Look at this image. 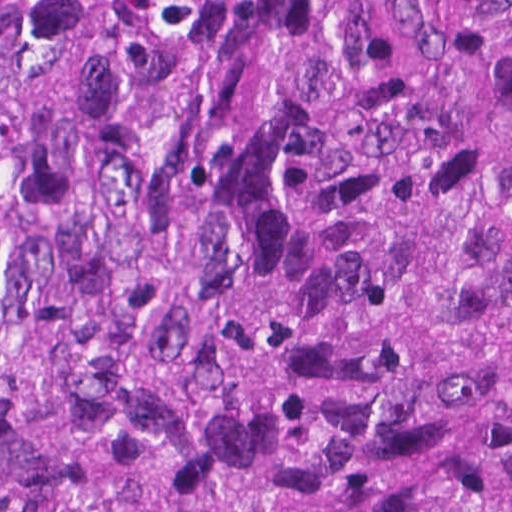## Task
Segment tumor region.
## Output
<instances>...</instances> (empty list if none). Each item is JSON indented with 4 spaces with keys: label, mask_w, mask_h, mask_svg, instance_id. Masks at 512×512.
Here are the masks:
<instances>
[{
    "label": "tumor region",
    "mask_w": 512,
    "mask_h": 512,
    "mask_svg": "<svg viewBox=\"0 0 512 512\" xmlns=\"http://www.w3.org/2000/svg\"><path fill=\"white\" fill-rule=\"evenodd\" d=\"M0 512H512V0H0Z\"/></svg>",
    "instance_id": "1"
}]
</instances>
